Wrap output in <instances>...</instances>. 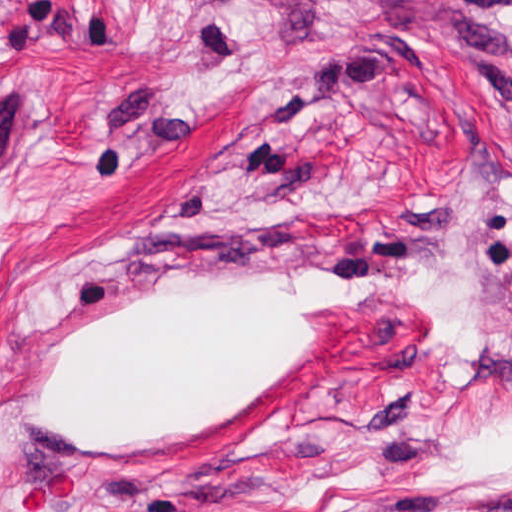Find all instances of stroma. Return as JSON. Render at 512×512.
<instances>
[{
	"mask_svg": "<svg viewBox=\"0 0 512 512\" xmlns=\"http://www.w3.org/2000/svg\"><path fill=\"white\" fill-rule=\"evenodd\" d=\"M0 512H512V0H0Z\"/></svg>",
	"mask_w": 512,
	"mask_h": 512,
	"instance_id": "obj_1",
	"label": "stroma"
}]
</instances>
